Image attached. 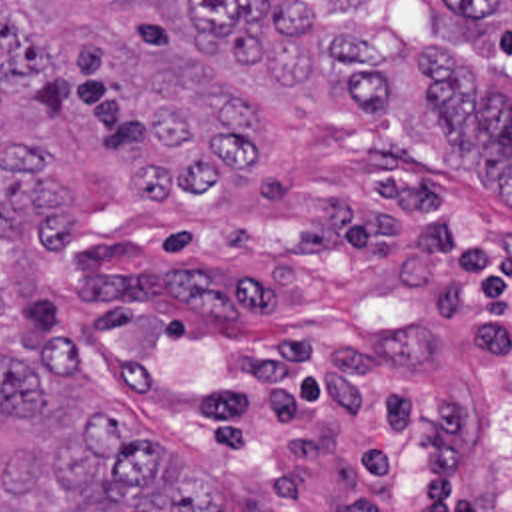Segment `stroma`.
Instances as JSON below:
<instances>
[{
  "label": "stroma",
  "instance_id": "35a3bbf8",
  "mask_svg": "<svg viewBox=\"0 0 512 512\" xmlns=\"http://www.w3.org/2000/svg\"><path fill=\"white\" fill-rule=\"evenodd\" d=\"M256 118L220 188L145 194L89 112L0 94V144L41 152L71 218L63 248L5 250L0 343L61 335L222 512H512V208L430 118Z\"/></svg>",
  "mask_w": 512,
  "mask_h": 512
}]
</instances>
